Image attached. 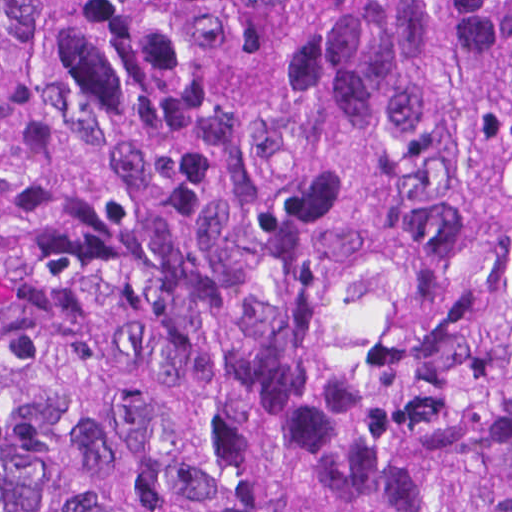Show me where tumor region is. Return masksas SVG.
<instances>
[{
    "instance_id": "e687c5a6",
    "label": "tumor region",
    "mask_w": 512,
    "mask_h": 512,
    "mask_svg": "<svg viewBox=\"0 0 512 512\" xmlns=\"http://www.w3.org/2000/svg\"><path fill=\"white\" fill-rule=\"evenodd\" d=\"M0 512H512V0H0Z\"/></svg>"
}]
</instances>
